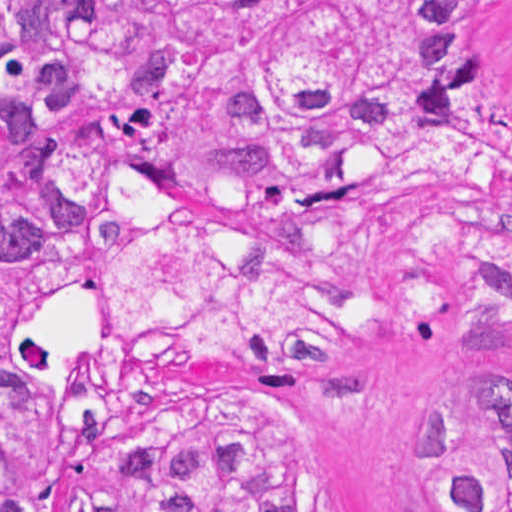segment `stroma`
<instances>
[{
	"label": "stroma",
	"instance_id": "stroma-1",
	"mask_svg": "<svg viewBox=\"0 0 512 512\" xmlns=\"http://www.w3.org/2000/svg\"><path fill=\"white\" fill-rule=\"evenodd\" d=\"M504 103L512 111V69ZM11 335L29 363L70 406L65 467L51 512L95 495V442L86 415L110 408L123 431L158 428L182 408L251 406L280 420L303 466L312 512H443L425 492L412 449L432 428L443 392L467 374L512 401V339L406 343L367 365L236 363L155 368L118 348L103 276L15 310Z\"/></svg>",
	"mask_w": 512,
	"mask_h": 512
}]
</instances>
